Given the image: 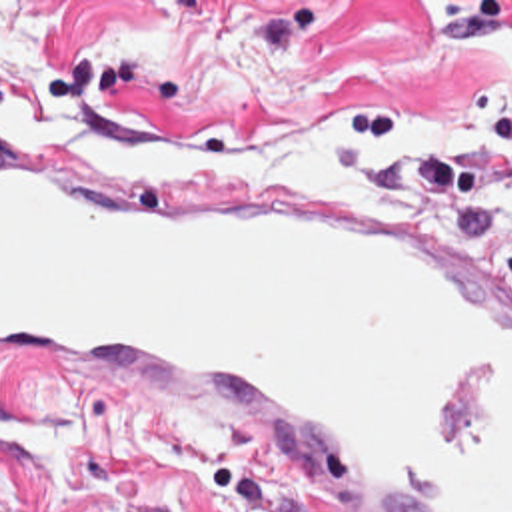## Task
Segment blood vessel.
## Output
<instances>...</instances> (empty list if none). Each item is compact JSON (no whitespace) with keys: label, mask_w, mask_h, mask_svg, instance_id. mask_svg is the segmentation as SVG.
<instances>
[{"label":"blood vessel","mask_w":512,"mask_h":512,"mask_svg":"<svg viewBox=\"0 0 512 512\" xmlns=\"http://www.w3.org/2000/svg\"><path fill=\"white\" fill-rule=\"evenodd\" d=\"M0 389L208 415L304 512H512V284L204 152L0 122Z\"/></svg>","instance_id":"1"}]
</instances>
